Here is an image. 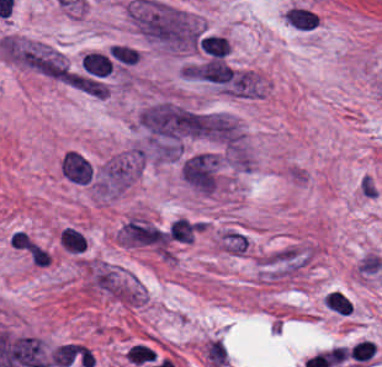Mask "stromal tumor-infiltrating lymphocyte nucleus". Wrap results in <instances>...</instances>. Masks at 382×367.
Returning a JSON list of instances; mask_svg holds the SVG:
<instances>
[{"mask_svg":"<svg viewBox=\"0 0 382 367\" xmlns=\"http://www.w3.org/2000/svg\"><path fill=\"white\" fill-rule=\"evenodd\" d=\"M357 270L365 277L382 279V257L376 252H368L361 258Z\"/></svg>","mask_w":382,"mask_h":367,"instance_id":"3","label":"stromal tumor-infiltrating lymphocyte nucleus"},{"mask_svg":"<svg viewBox=\"0 0 382 367\" xmlns=\"http://www.w3.org/2000/svg\"><path fill=\"white\" fill-rule=\"evenodd\" d=\"M324 305L338 314L346 316L351 314L352 304L340 290H333L325 295Z\"/></svg>","mask_w":382,"mask_h":367,"instance_id":"4","label":"stromal tumor-infiltrating lymphocyte nucleus"},{"mask_svg":"<svg viewBox=\"0 0 382 367\" xmlns=\"http://www.w3.org/2000/svg\"><path fill=\"white\" fill-rule=\"evenodd\" d=\"M376 349L373 341L361 340L350 350V358L355 362H368L373 358Z\"/></svg>","mask_w":382,"mask_h":367,"instance_id":"7","label":"stromal tumor-infiltrating lymphocyte nucleus"},{"mask_svg":"<svg viewBox=\"0 0 382 367\" xmlns=\"http://www.w3.org/2000/svg\"><path fill=\"white\" fill-rule=\"evenodd\" d=\"M108 51L114 58L124 64H135L140 59L137 52L131 46L125 44H112Z\"/></svg>","mask_w":382,"mask_h":367,"instance_id":"6","label":"stromal tumor-infiltrating lymphocyte nucleus"},{"mask_svg":"<svg viewBox=\"0 0 382 367\" xmlns=\"http://www.w3.org/2000/svg\"><path fill=\"white\" fill-rule=\"evenodd\" d=\"M356 189L359 197L362 199L374 200L379 194V188L375 179L366 172L360 175Z\"/></svg>","mask_w":382,"mask_h":367,"instance_id":"5","label":"stromal tumor-infiltrating lymphocyte nucleus"},{"mask_svg":"<svg viewBox=\"0 0 382 367\" xmlns=\"http://www.w3.org/2000/svg\"><path fill=\"white\" fill-rule=\"evenodd\" d=\"M59 243L72 253H79L87 246L83 235L72 226H65L62 229Z\"/></svg>","mask_w":382,"mask_h":367,"instance_id":"2","label":"stromal tumor-infiltrating lymphocyte nucleus"},{"mask_svg":"<svg viewBox=\"0 0 382 367\" xmlns=\"http://www.w3.org/2000/svg\"><path fill=\"white\" fill-rule=\"evenodd\" d=\"M198 43L212 57H225L231 51L230 41L224 36L206 35Z\"/></svg>","mask_w":382,"mask_h":367,"instance_id":"1","label":"stromal tumor-infiltrating lymphocyte nucleus"}]
</instances>
